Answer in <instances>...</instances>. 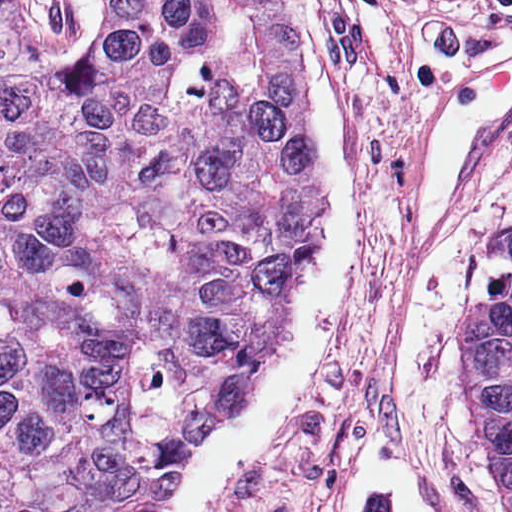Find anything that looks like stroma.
I'll return each mask as SVG.
<instances>
[{"label": "stroma", "mask_w": 512, "mask_h": 512, "mask_svg": "<svg viewBox=\"0 0 512 512\" xmlns=\"http://www.w3.org/2000/svg\"><path fill=\"white\" fill-rule=\"evenodd\" d=\"M19 2L59 60L80 64L92 46L75 61L63 0ZM334 2L360 115V304L305 412L226 512H335L374 436L413 463L435 512H512L465 390L469 308L512 272V123L457 189L439 250L419 248L410 218L419 145L510 33L512 0Z\"/></svg>", "instance_id": "1"}]
</instances>
